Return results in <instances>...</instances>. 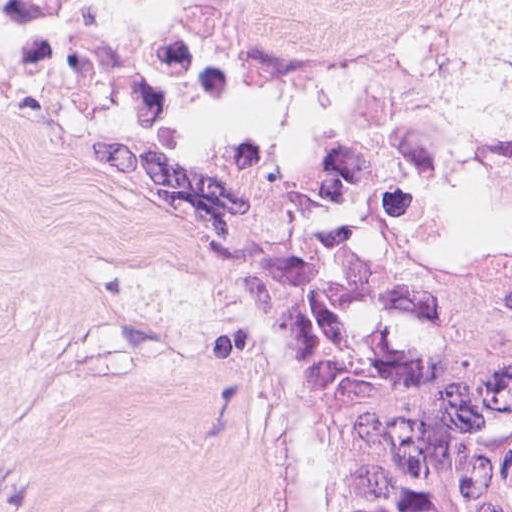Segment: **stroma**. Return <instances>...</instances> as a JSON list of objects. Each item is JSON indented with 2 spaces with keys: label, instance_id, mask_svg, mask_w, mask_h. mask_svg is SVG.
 Segmentation results:
<instances>
[{
  "label": "stroma",
  "instance_id": "1",
  "mask_svg": "<svg viewBox=\"0 0 512 512\" xmlns=\"http://www.w3.org/2000/svg\"><path fill=\"white\" fill-rule=\"evenodd\" d=\"M396 83L446 101L445 210L512 238L483 126L512 0H0V512H306V468L194 267L93 219L99 141L193 94L270 139Z\"/></svg>",
  "mask_w": 512,
  "mask_h": 512
}]
</instances>
